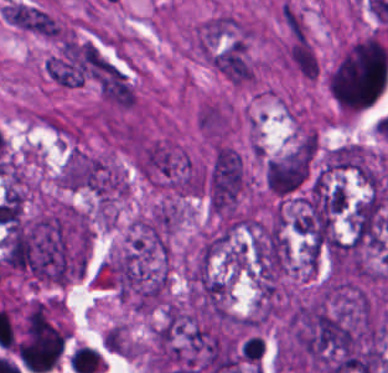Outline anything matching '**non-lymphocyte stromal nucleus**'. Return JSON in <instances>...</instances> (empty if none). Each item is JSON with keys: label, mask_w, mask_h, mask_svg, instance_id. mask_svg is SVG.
Instances as JSON below:
<instances>
[{"label": "non-lymphocyte stromal nucleus", "mask_w": 388, "mask_h": 373, "mask_svg": "<svg viewBox=\"0 0 388 373\" xmlns=\"http://www.w3.org/2000/svg\"><path fill=\"white\" fill-rule=\"evenodd\" d=\"M198 123L206 132L222 135L227 121L222 107L207 103L198 110Z\"/></svg>", "instance_id": "non-lymphocyte-stromal-nucleus-4"}, {"label": "non-lymphocyte stromal nucleus", "mask_w": 388, "mask_h": 373, "mask_svg": "<svg viewBox=\"0 0 388 373\" xmlns=\"http://www.w3.org/2000/svg\"><path fill=\"white\" fill-rule=\"evenodd\" d=\"M282 13L286 29L290 35L309 41L308 26L305 14L290 1H283Z\"/></svg>", "instance_id": "non-lymphocyte-stromal-nucleus-5"}, {"label": "non-lymphocyte stromal nucleus", "mask_w": 388, "mask_h": 373, "mask_svg": "<svg viewBox=\"0 0 388 373\" xmlns=\"http://www.w3.org/2000/svg\"><path fill=\"white\" fill-rule=\"evenodd\" d=\"M285 59L299 74L309 79L319 76V60L309 41L291 39Z\"/></svg>", "instance_id": "non-lymphocyte-stromal-nucleus-3"}, {"label": "non-lymphocyte stromal nucleus", "mask_w": 388, "mask_h": 373, "mask_svg": "<svg viewBox=\"0 0 388 373\" xmlns=\"http://www.w3.org/2000/svg\"><path fill=\"white\" fill-rule=\"evenodd\" d=\"M245 184V165L240 152L225 143L212 150L206 175L209 209L219 215H233Z\"/></svg>", "instance_id": "non-lymphocyte-stromal-nucleus-1"}, {"label": "non-lymphocyte stromal nucleus", "mask_w": 388, "mask_h": 373, "mask_svg": "<svg viewBox=\"0 0 388 373\" xmlns=\"http://www.w3.org/2000/svg\"><path fill=\"white\" fill-rule=\"evenodd\" d=\"M143 176L173 190H193V169L186 154L166 139L147 138L139 147Z\"/></svg>", "instance_id": "non-lymphocyte-stromal-nucleus-2"}]
</instances>
